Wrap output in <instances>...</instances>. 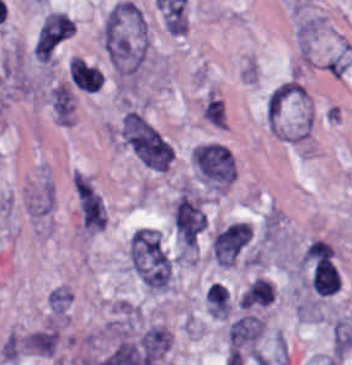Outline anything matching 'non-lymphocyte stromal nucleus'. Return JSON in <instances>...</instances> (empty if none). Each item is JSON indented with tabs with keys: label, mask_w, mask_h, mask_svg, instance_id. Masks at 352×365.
<instances>
[{
	"label": "non-lymphocyte stromal nucleus",
	"mask_w": 352,
	"mask_h": 365,
	"mask_svg": "<svg viewBox=\"0 0 352 365\" xmlns=\"http://www.w3.org/2000/svg\"><path fill=\"white\" fill-rule=\"evenodd\" d=\"M333 247L322 238H315L301 255L302 263L332 258Z\"/></svg>",
	"instance_id": "non-lymphocyte-stromal-nucleus-14"
},
{
	"label": "non-lymphocyte stromal nucleus",
	"mask_w": 352,
	"mask_h": 365,
	"mask_svg": "<svg viewBox=\"0 0 352 365\" xmlns=\"http://www.w3.org/2000/svg\"><path fill=\"white\" fill-rule=\"evenodd\" d=\"M273 298V288L269 282L261 277H256L243 291L239 301L242 307L265 305Z\"/></svg>",
	"instance_id": "non-lymphocyte-stromal-nucleus-10"
},
{
	"label": "non-lymphocyte stromal nucleus",
	"mask_w": 352,
	"mask_h": 365,
	"mask_svg": "<svg viewBox=\"0 0 352 365\" xmlns=\"http://www.w3.org/2000/svg\"><path fill=\"white\" fill-rule=\"evenodd\" d=\"M73 183L77 193L80 206L87 210H95L99 208L101 199L93 187L74 170Z\"/></svg>",
	"instance_id": "non-lymphocyte-stromal-nucleus-13"
},
{
	"label": "non-lymphocyte stromal nucleus",
	"mask_w": 352,
	"mask_h": 365,
	"mask_svg": "<svg viewBox=\"0 0 352 365\" xmlns=\"http://www.w3.org/2000/svg\"><path fill=\"white\" fill-rule=\"evenodd\" d=\"M263 328L255 313H242L228 323L226 365H231L258 354Z\"/></svg>",
	"instance_id": "non-lymphocyte-stromal-nucleus-4"
},
{
	"label": "non-lymphocyte stromal nucleus",
	"mask_w": 352,
	"mask_h": 365,
	"mask_svg": "<svg viewBox=\"0 0 352 365\" xmlns=\"http://www.w3.org/2000/svg\"><path fill=\"white\" fill-rule=\"evenodd\" d=\"M207 308L214 317H227L229 298L227 286L219 281H212L206 290Z\"/></svg>",
	"instance_id": "non-lymphocyte-stromal-nucleus-11"
},
{
	"label": "non-lymphocyte stromal nucleus",
	"mask_w": 352,
	"mask_h": 365,
	"mask_svg": "<svg viewBox=\"0 0 352 365\" xmlns=\"http://www.w3.org/2000/svg\"><path fill=\"white\" fill-rule=\"evenodd\" d=\"M74 32V22L69 16L51 10L43 16L39 26L35 50L38 54H50Z\"/></svg>",
	"instance_id": "non-lymphocyte-stromal-nucleus-8"
},
{
	"label": "non-lymphocyte stromal nucleus",
	"mask_w": 352,
	"mask_h": 365,
	"mask_svg": "<svg viewBox=\"0 0 352 365\" xmlns=\"http://www.w3.org/2000/svg\"><path fill=\"white\" fill-rule=\"evenodd\" d=\"M131 271L146 289L169 286L170 259L158 231L136 230L127 246Z\"/></svg>",
	"instance_id": "non-lymphocyte-stromal-nucleus-2"
},
{
	"label": "non-lymphocyte stromal nucleus",
	"mask_w": 352,
	"mask_h": 365,
	"mask_svg": "<svg viewBox=\"0 0 352 365\" xmlns=\"http://www.w3.org/2000/svg\"><path fill=\"white\" fill-rule=\"evenodd\" d=\"M252 237L248 222H234L213 238L212 253L218 265H232Z\"/></svg>",
	"instance_id": "non-lymphocyte-stromal-nucleus-7"
},
{
	"label": "non-lymphocyte stromal nucleus",
	"mask_w": 352,
	"mask_h": 365,
	"mask_svg": "<svg viewBox=\"0 0 352 365\" xmlns=\"http://www.w3.org/2000/svg\"><path fill=\"white\" fill-rule=\"evenodd\" d=\"M122 140L137 159L153 169H166L173 155L167 140L140 112L123 115Z\"/></svg>",
	"instance_id": "non-lymphocyte-stromal-nucleus-3"
},
{
	"label": "non-lymphocyte stromal nucleus",
	"mask_w": 352,
	"mask_h": 365,
	"mask_svg": "<svg viewBox=\"0 0 352 365\" xmlns=\"http://www.w3.org/2000/svg\"><path fill=\"white\" fill-rule=\"evenodd\" d=\"M145 24L138 9L127 0L111 7L104 19L101 42L113 68L131 73L142 58Z\"/></svg>",
	"instance_id": "non-lymphocyte-stromal-nucleus-1"
},
{
	"label": "non-lymphocyte stromal nucleus",
	"mask_w": 352,
	"mask_h": 365,
	"mask_svg": "<svg viewBox=\"0 0 352 365\" xmlns=\"http://www.w3.org/2000/svg\"><path fill=\"white\" fill-rule=\"evenodd\" d=\"M193 160L201 179L217 185L229 184L234 177L235 163L231 153L217 142L194 148Z\"/></svg>",
	"instance_id": "non-lymphocyte-stromal-nucleus-5"
},
{
	"label": "non-lymphocyte stromal nucleus",
	"mask_w": 352,
	"mask_h": 365,
	"mask_svg": "<svg viewBox=\"0 0 352 365\" xmlns=\"http://www.w3.org/2000/svg\"><path fill=\"white\" fill-rule=\"evenodd\" d=\"M51 104L59 120H69L73 109V98L67 85L61 81L49 90Z\"/></svg>",
	"instance_id": "non-lymphocyte-stromal-nucleus-12"
},
{
	"label": "non-lymphocyte stromal nucleus",
	"mask_w": 352,
	"mask_h": 365,
	"mask_svg": "<svg viewBox=\"0 0 352 365\" xmlns=\"http://www.w3.org/2000/svg\"><path fill=\"white\" fill-rule=\"evenodd\" d=\"M68 73L70 80L83 91H96L102 84L100 70L80 58H69Z\"/></svg>",
	"instance_id": "non-lymphocyte-stromal-nucleus-9"
},
{
	"label": "non-lymphocyte stromal nucleus",
	"mask_w": 352,
	"mask_h": 365,
	"mask_svg": "<svg viewBox=\"0 0 352 365\" xmlns=\"http://www.w3.org/2000/svg\"><path fill=\"white\" fill-rule=\"evenodd\" d=\"M105 223V213L102 202L84 211L81 224L89 230L103 228Z\"/></svg>",
	"instance_id": "non-lymphocyte-stromal-nucleus-15"
},
{
	"label": "non-lymphocyte stromal nucleus",
	"mask_w": 352,
	"mask_h": 365,
	"mask_svg": "<svg viewBox=\"0 0 352 365\" xmlns=\"http://www.w3.org/2000/svg\"><path fill=\"white\" fill-rule=\"evenodd\" d=\"M175 230L186 247H195L207 220L198 202L181 188L174 206Z\"/></svg>",
	"instance_id": "non-lymphocyte-stromal-nucleus-6"
}]
</instances>
